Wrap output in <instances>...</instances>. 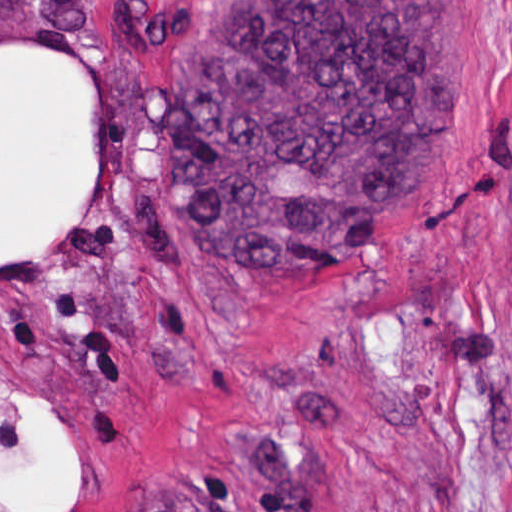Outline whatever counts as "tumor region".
Wrapping results in <instances>:
<instances>
[{
	"label": "tumor region",
	"instance_id": "1",
	"mask_svg": "<svg viewBox=\"0 0 512 512\" xmlns=\"http://www.w3.org/2000/svg\"><path fill=\"white\" fill-rule=\"evenodd\" d=\"M175 48L162 178L249 269H333L418 203L460 105L462 1H199Z\"/></svg>",
	"mask_w": 512,
	"mask_h": 512
}]
</instances>
